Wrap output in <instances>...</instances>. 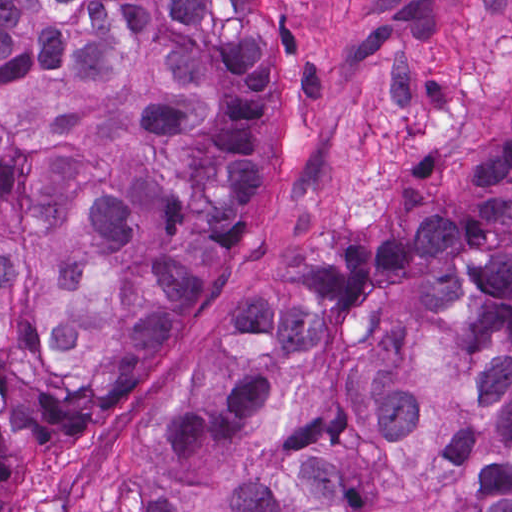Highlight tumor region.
Returning a JSON list of instances; mask_svg holds the SVG:
<instances>
[{"label":"tumor region","mask_w":512,"mask_h":512,"mask_svg":"<svg viewBox=\"0 0 512 512\" xmlns=\"http://www.w3.org/2000/svg\"><path fill=\"white\" fill-rule=\"evenodd\" d=\"M257 0H0V512L134 408L262 191ZM150 512H512V111L322 246L160 429Z\"/></svg>","instance_id":"tumor-region-1"}]
</instances>
